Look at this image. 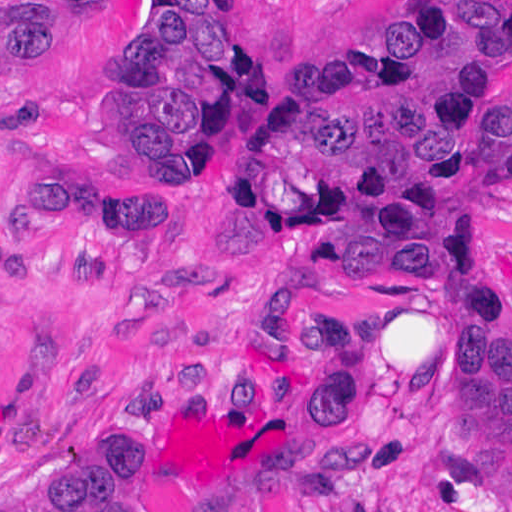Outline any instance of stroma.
<instances>
[{"label":"stroma","mask_w":512,"mask_h":512,"mask_svg":"<svg viewBox=\"0 0 512 512\" xmlns=\"http://www.w3.org/2000/svg\"><path fill=\"white\" fill-rule=\"evenodd\" d=\"M248 85L192 176H159L113 137L100 84L139 30L143 0L72 9L24 81L0 90V228L36 264L34 287L0 277V512L138 443L178 512H246L262 479L308 462L318 415L255 370L299 365L316 318L360 326L347 429L372 452L340 512H512V464L458 450V378L435 295L387 232L236 195L267 110L309 57L358 50L418 0H218ZM476 79L512 98V34L476 52ZM54 162L144 207H179L178 235L126 237L121 270L80 283L70 246L5 226L24 169ZM442 217L437 242L512 284V189ZM5 226V229H4ZM335 247L386 276H339Z\"/></svg>","instance_id":"1"}]
</instances>
